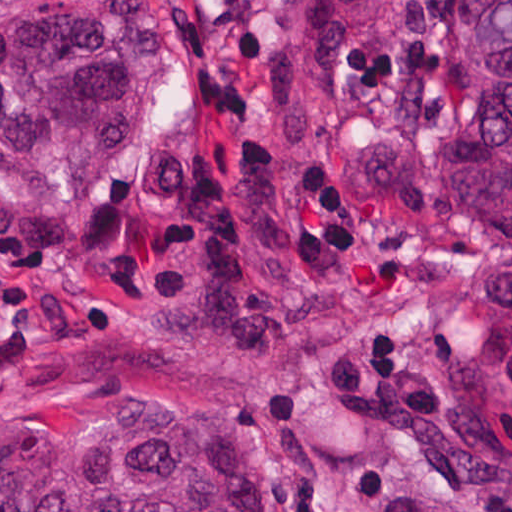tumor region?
Returning a JSON list of instances; mask_svg holds the SVG:
<instances>
[{
    "mask_svg": "<svg viewBox=\"0 0 512 512\" xmlns=\"http://www.w3.org/2000/svg\"><path fill=\"white\" fill-rule=\"evenodd\" d=\"M291 29L259 64L291 139L325 131L341 62L363 37L434 90L437 141L330 133L342 175L386 201L432 173L468 241L512 256V0H289ZM175 33L153 0H0V195L61 202L102 173L169 70ZM469 413L512 472V353L469 373ZM385 512H489L392 494ZM0 512H277L255 439L223 410L115 404L0 426Z\"/></svg>",
    "mask_w": 512,
    "mask_h": 512,
    "instance_id": "1",
    "label": "tumor region"
}]
</instances>
